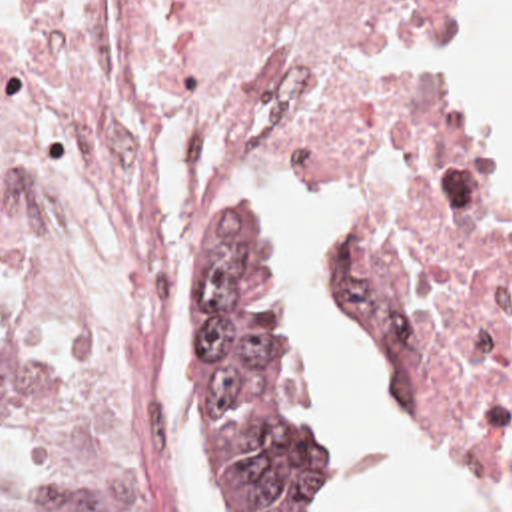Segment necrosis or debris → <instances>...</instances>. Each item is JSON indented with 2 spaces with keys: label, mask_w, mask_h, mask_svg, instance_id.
<instances>
[{
  "label": "necrosis or debris",
  "mask_w": 512,
  "mask_h": 512,
  "mask_svg": "<svg viewBox=\"0 0 512 512\" xmlns=\"http://www.w3.org/2000/svg\"><path fill=\"white\" fill-rule=\"evenodd\" d=\"M461 0H0V290L53 356L29 451L181 512L149 342L157 152L181 124L379 194L353 264L411 391L512 475V234L453 154Z\"/></svg>",
  "instance_id": "necrosis-or-debris-1"
}]
</instances>
